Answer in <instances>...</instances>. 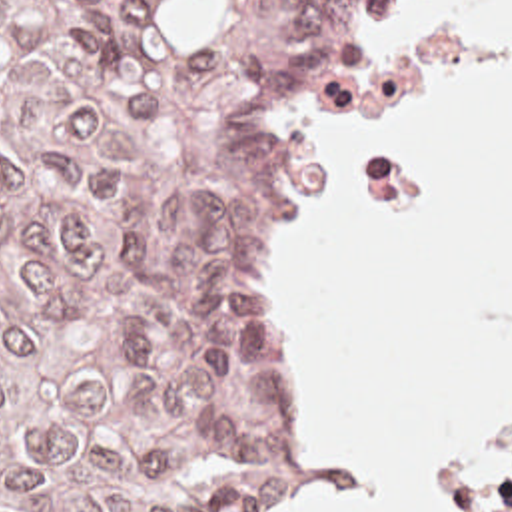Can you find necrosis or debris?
<instances>
[{
  "instance_id": "4bbe7bcc",
  "label": "necrosis or debris",
  "mask_w": 512,
  "mask_h": 512,
  "mask_svg": "<svg viewBox=\"0 0 512 512\" xmlns=\"http://www.w3.org/2000/svg\"><path fill=\"white\" fill-rule=\"evenodd\" d=\"M440 490L458 512H512V442Z\"/></svg>"
}]
</instances>
